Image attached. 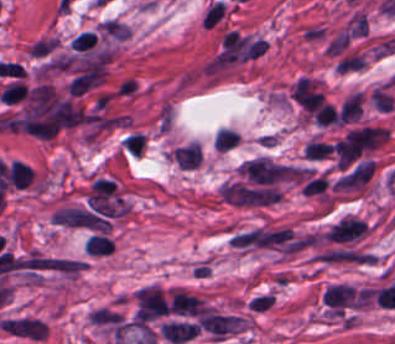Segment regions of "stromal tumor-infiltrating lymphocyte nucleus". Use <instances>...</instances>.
Listing matches in <instances>:
<instances>
[{
  "instance_id": "obj_1",
  "label": "stromal tumor-infiltrating lymphocyte nucleus",
  "mask_w": 395,
  "mask_h": 344,
  "mask_svg": "<svg viewBox=\"0 0 395 344\" xmlns=\"http://www.w3.org/2000/svg\"><path fill=\"white\" fill-rule=\"evenodd\" d=\"M224 14L225 5L216 0L204 15L203 26L212 27Z\"/></svg>"
}]
</instances>
